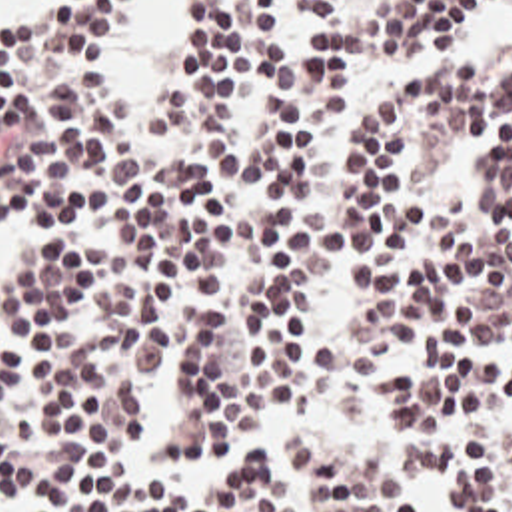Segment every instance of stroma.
<instances>
[{
  "label": "stroma",
  "instance_id": "stroma-1",
  "mask_svg": "<svg viewBox=\"0 0 512 512\" xmlns=\"http://www.w3.org/2000/svg\"><path fill=\"white\" fill-rule=\"evenodd\" d=\"M127 1H121L119 13L117 17L123 13ZM43 5V0H37L31 11L25 13H17L11 17H3L1 21L7 25H23L31 19L37 17L39 9ZM115 17V21H117ZM471 51L475 55H497V57H505L512 61V13H503V11H493L477 29H473L469 35H465L463 39L455 41L453 45L423 55L419 59H413L389 73H385L383 77H379L373 83L361 85L353 91L351 99H367L371 95H377L381 91H387L391 87L401 85L405 79H409L415 71L427 67L429 63L447 57L451 53L457 51ZM109 79V77H107ZM129 103H149V101H129ZM273 411H287L297 426L307 425V423H315V421H323V419H345V421H353L359 425L367 426L371 432H375L391 450V456H397L409 442V430L401 423H393V421H385L381 417H377L375 413H371L369 409H301V407H251L245 413H241L243 426L255 436V428L259 423L271 415ZM267 502L271 506L273 512H285V500L279 492V488L275 486V482L271 480V476L267 474ZM415 512H455L449 498L443 492L437 490H429L423 482L419 484V488L415 490Z\"/></svg>",
  "mask_w": 512,
  "mask_h": 512
}]
</instances>
